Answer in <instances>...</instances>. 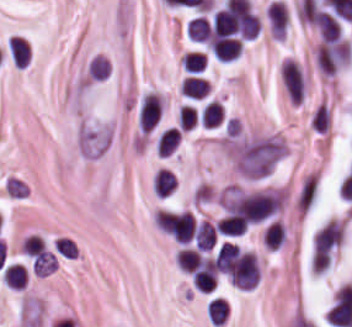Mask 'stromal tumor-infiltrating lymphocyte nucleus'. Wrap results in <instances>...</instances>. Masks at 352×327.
<instances>
[{"label": "stromal tumor-infiltrating lymphocyte nucleus", "mask_w": 352, "mask_h": 327, "mask_svg": "<svg viewBox=\"0 0 352 327\" xmlns=\"http://www.w3.org/2000/svg\"><path fill=\"white\" fill-rule=\"evenodd\" d=\"M239 261H240L239 250L234 243L224 240L216 249V253H215L216 269H218L228 277L235 278Z\"/></svg>", "instance_id": "8"}, {"label": "stromal tumor-infiltrating lymphocyte nucleus", "mask_w": 352, "mask_h": 327, "mask_svg": "<svg viewBox=\"0 0 352 327\" xmlns=\"http://www.w3.org/2000/svg\"><path fill=\"white\" fill-rule=\"evenodd\" d=\"M26 268L22 263L11 262L4 266L2 279L7 286L23 287Z\"/></svg>", "instance_id": "20"}, {"label": "stromal tumor-infiltrating lymphocyte nucleus", "mask_w": 352, "mask_h": 327, "mask_svg": "<svg viewBox=\"0 0 352 327\" xmlns=\"http://www.w3.org/2000/svg\"><path fill=\"white\" fill-rule=\"evenodd\" d=\"M175 262L180 269L192 271L201 264V255L197 248L182 246L175 255Z\"/></svg>", "instance_id": "18"}, {"label": "stromal tumor-infiltrating lymphocyte nucleus", "mask_w": 352, "mask_h": 327, "mask_svg": "<svg viewBox=\"0 0 352 327\" xmlns=\"http://www.w3.org/2000/svg\"><path fill=\"white\" fill-rule=\"evenodd\" d=\"M212 23L211 16L207 13L196 12L188 20L185 26V34L195 44H207L211 39Z\"/></svg>", "instance_id": "5"}, {"label": "stromal tumor-infiltrating lymphocyte nucleus", "mask_w": 352, "mask_h": 327, "mask_svg": "<svg viewBox=\"0 0 352 327\" xmlns=\"http://www.w3.org/2000/svg\"><path fill=\"white\" fill-rule=\"evenodd\" d=\"M352 55V46L343 39L327 41L317 52L316 62L320 71L326 75H334Z\"/></svg>", "instance_id": "3"}, {"label": "stromal tumor-infiltrating lymphocyte nucleus", "mask_w": 352, "mask_h": 327, "mask_svg": "<svg viewBox=\"0 0 352 327\" xmlns=\"http://www.w3.org/2000/svg\"><path fill=\"white\" fill-rule=\"evenodd\" d=\"M281 82L289 97L297 103L303 99L304 82L299 67L292 59L281 63Z\"/></svg>", "instance_id": "4"}, {"label": "stromal tumor-infiltrating lymphocyte nucleus", "mask_w": 352, "mask_h": 327, "mask_svg": "<svg viewBox=\"0 0 352 327\" xmlns=\"http://www.w3.org/2000/svg\"><path fill=\"white\" fill-rule=\"evenodd\" d=\"M258 275L259 268L256 257L247 250L243 253L231 282L238 287L251 288L258 280Z\"/></svg>", "instance_id": "6"}, {"label": "stromal tumor-infiltrating lymphocyte nucleus", "mask_w": 352, "mask_h": 327, "mask_svg": "<svg viewBox=\"0 0 352 327\" xmlns=\"http://www.w3.org/2000/svg\"><path fill=\"white\" fill-rule=\"evenodd\" d=\"M13 66L23 67L29 58V46L23 37L10 36L7 39Z\"/></svg>", "instance_id": "14"}, {"label": "stromal tumor-infiltrating lymphocyte nucleus", "mask_w": 352, "mask_h": 327, "mask_svg": "<svg viewBox=\"0 0 352 327\" xmlns=\"http://www.w3.org/2000/svg\"><path fill=\"white\" fill-rule=\"evenodd\" d=\"M154 192L158 196H166L176 187V178L170 169L159 168L153 175Z\"/></svg>", "instance_id": "17"}, {"label": "stromal tumor-infiltrating lymphocyte nucleus", "mask_w": 352, "mask_h": 327, "mask_svg": "<svg viewBox=\"0 0 352 327\" xmlns=\"http://www.w3.org/2000/svg\"><path fill=\"white\" fill-rule=\"evenodd\" d=\"M216 236L217 233L212 222L208 219H201L195 228V244L202 250H209L212 248Z\"/></svg>", "instance_id": "13"}, {"label": "stromal tumor-infiltrating lymphocyte nucleus", "mask_w": 352, "mask_h": 327, "mask_svg": "<svg viewBox=\"0 0 352 327\" xmlns=\"http://www.w3.org/2000/svg\"><path fill=\"white\" fill-rule=\"evenodd\" d=\"M248 219L237 212H229L219 219L218 232L226 235H240L248 226Z\"/></svg>", "instance_id": "11"}, {"label": "stromal tumor-infiltrating lymphocyte nucleus", "mask_w": 352, "mask_h": 327, "mask_svg": "<svg viewBox=\"0 0 352 327\" xmlns=\"http://www.w3.org/2000/svg\"><path fill=\"white\" fill-rule=\"evenodd\" d=\"M206 65V55L201 50H187L183 66L187 71H201Z\"/></svg>", "instance_id": "23"}, {"label": "stromal tumor-infiltrating lymphocyte nucleus", "mask_w": 352, "mask_h": 327, "mask_svg": "<svg viewBox=\"0 0 352 327\" xmlns=\"http://www.w3.org/2000/svg\"><path fill=\"white\" fill-rule=\"evenodd\" d=\"M343 239V231L333 218L314 235L312 262L329 264Z\"/></svg>", "instance_id": "2"}, {"label": "stromal tumor-infiltrating lymphocyte nucleus", "mask_w": 352, "mask_h": 327, "mask_svg": "<svg viewBox=\"0 0 352 327\" xmlns=\"http://www.w3.org/2000/svg\"><path fill=\"white\" fill-rule=\"evenodd\" d=\"M181 139V132L176 126H169L162 130L155 146L157 153L166 155L174 150Z\"/></svg>", "instance_id": "15"}, {"label": "stromal tumor-infiltrating lymphocyte nucleus", "mask_w": 352, "mask_h": 327, "mask_svg": "<svg viewBox=\"0 0 352 327\" xmlns=\"http://www.w3.org/2000/svg\"><path fill=\"white\" fill-rule=\"evenodd\" d=\"M280 203L281 195L275 192L253 191L224 201L223 207L227 213L250 223L274 213Z\"/></svg>", "instance_id": "1"}, {"label": "stromal tumor-infiltrating lymphocyte nucleus", "mask_w": 352, "mask_h": 327, "mask_svg": "<svg viewBox=\"0 0 352 327\" xmlns=\"http://www.w3.org/2000/svg\"><path fill=\"white\" fill-rule=\"evenodd\" d=\"M206 314L211 324H219L228 314V307L219 297H211L206 303Z\"/></svg>", "instance_id": "21"}, {"label": "stromal tumor-infiltrating lymphocyte nucleus", "mask_w": 352, "mask_h": 327, "mask_svg": "<svg viewBox=\"0 0 352 327\" xmlns=\"http://www.w3.org/2000/svg\"><path fill=\"white\" fill-rule=\"evenodd\" d=\"M210 46L218 57L230 60L238 56L242 44L234 37L220 36L212 39Z\"/></svg>", "instance_id": "10"}, {"label": "stromal tumor-infiltrating lymphocyte nucleus", "mask_w": 352, "mask_h": 327, "mask_svg": "<svg viewBox=\"0 0 352 327\" xmlns=\"http://www.w3.org/2000/svg\"><path fill=\"white\" fill-rule=\"evenodd\" d=\"M161 115L160 95L147 91L138 107L137 120L141 129H150Z\"/></svg>", "instance_id": "7"}, {"label": "stromal tumor-infiltrating lymphocyte nucleus", "mask_w": 352, "mask_h": 327, "mask_svg": "<svg viewBox=\"0 0 352 327\" xmlns=\"http://www.w3.org/2000/svg\"><path fill=\"white\" fill-rule=\"evenodd\" d=\"M271 37L283 38L286 27V5L279 0H271L265 10Z\"/></svg>", "instance_id": "9"}, {"label": "stromal tumor-infiltrating lymphocyte nucleus", "mask_w": 352, "mask_h": 327, "mask_svg": "<svg viewBox=\"0 0 352 327\" xmlns=\"http://www.w3.org/2000/svg\"><path fill=\"white\" fill-rule=\"evenodd\" d=\"M285 231L280 219H273L263 231L262 241L268 249H275L282 244Z\"/></svg>", "instance_id": "16"}, {"label": "stromal tumor-infiltrating lymphocyte nucleus", "mask_w": 352, "mask_h": 327, "mask_svg": "<svg viewBox=\"0 0 352 327\" xmlns=\"http://www.w3.org/2000/svg\"><path fill=\"white\" fill-rule=\"evenodd\" d=\"M208 90L207 80L200 76H186L181 86V92L191 98L206 96Z\"/></svg>", "instance_id": "19"}, {"label": "stromal tumor-infiltrating lymphocyte nucleus", "mask_w": 352, "mask_h": 327, "mask_svg": "<svg viewBox=\"0 0 352 327\" xmlns=\"http://www.w3.org/2000/svg\"><path fill=\"white\" fill-rule=\"evenodd\" d=\"M315 22L324 40H335L341 32L335 17L330 12L323 10L317 12Z\"/></svg>", "instance_id": "12"}, {"label": "stromal tumor-infiltrating lymphocyte nucleus", "mask_w": 352, "mask_h": 327, "mask_svg": "<svg viewBox=\"0 0 352 327\" xmlns=\"http://www.w3.org/2000/svg\"><path fill=\"white\" fill-rule=\"evenodd\" d=\"M222 116L223 107L221 102L212 99L202 106L200 114L202 123L212 127L222 119Z\"/></svg>", "instance_id": "22"}]
</instances>
